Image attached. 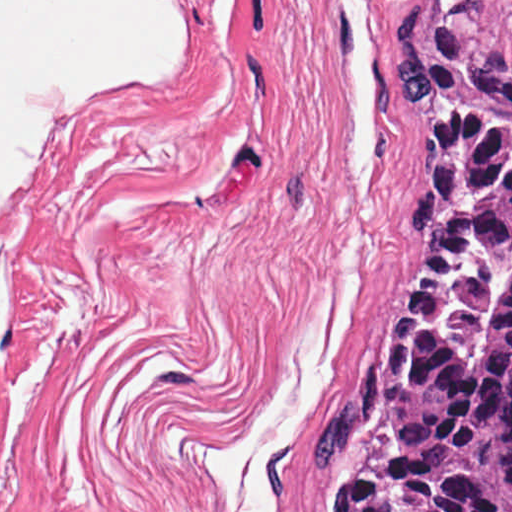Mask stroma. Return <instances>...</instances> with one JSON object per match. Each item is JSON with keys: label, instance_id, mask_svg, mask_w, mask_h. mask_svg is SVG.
Here are the masks:
<instances>
[{"label": "stroma", "instance_id": "1", "mask_svg": "<svg viewBox=\"0 0 512 512\" xmlns=\"http://www.w3.org/2000/svg\"><path fill=\"white\" fill-rule=\"evenodd\" d=\"M391 23L197 0L144 512H318L323 418L421 251Z\"/></svg>", "mask_w": 512, "mask_h": 512}]
</instances>
